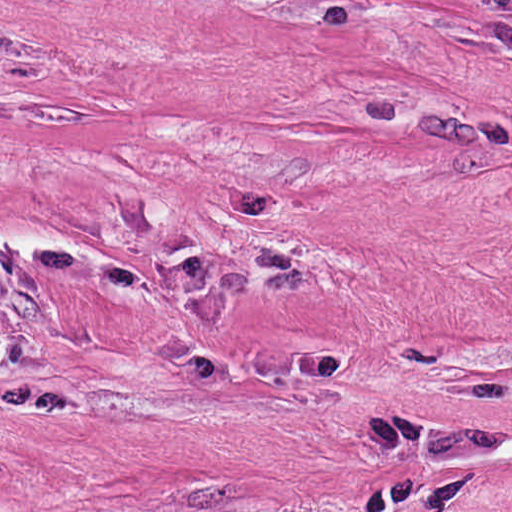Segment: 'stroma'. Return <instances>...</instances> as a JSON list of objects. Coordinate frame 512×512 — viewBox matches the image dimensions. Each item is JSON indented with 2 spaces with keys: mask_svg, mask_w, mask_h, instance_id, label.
<instances>
[{
  "mask_svg": "<svg viewBox=\"0 0 512 512\" xmlns=\"http://www.w3.org/2000/svg\"><path fill=\"white\" fill-rule=\"evenodd\" d=\"M512 131V0H110Z\"/></svg>",
  "mask_w": 512,
  "mask_h": 512,
  "instance_id": "obj_1",
  "label": "stroma"
}]
</instances>
